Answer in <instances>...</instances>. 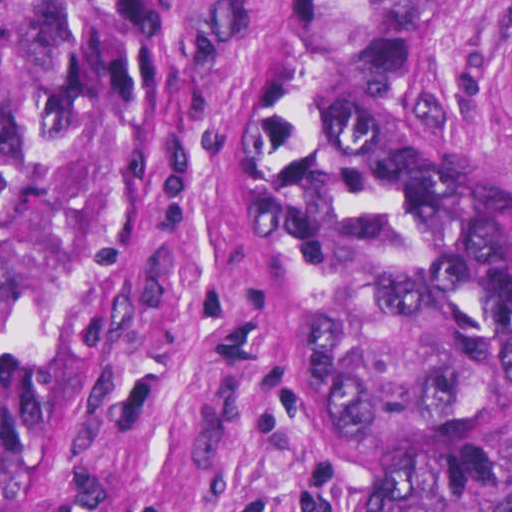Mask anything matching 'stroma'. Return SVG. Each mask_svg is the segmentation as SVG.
Instances as JSON below:
<instances>
[{
  "label": "stroma",
  "instance_id": "obj_1",
  "mask_svg": "<svg viewBox=\"0 0 512 512\" xmlns=\"http://www.w3.org/2000/svg\"><path fill=\"white\" fill-rule=\"evenodd\" d=\"M130 1L148 96L115 255L64 381L36 512H219L268 480V512L315 492L360 512L364 452L276 371L236 226V122L275 1H467L427 42V90L512 186V142L479 104L512 0Z\"/></svg>",
  "mask_w": 512,
  "mask_h": 512
}]
</instances>
